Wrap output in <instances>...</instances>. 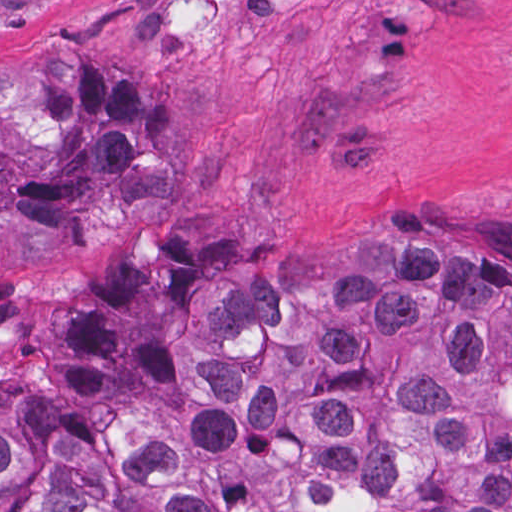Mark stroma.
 <instances>
[{
    "mask_svg": "<svg viewBox=\"0 0 512 512\" xmlns=\"http://www.w3.org/2000/svg\"><path fill=\"white\" fill-rule=\"evenodd\" d=\"M96 39L193 87L184 156L0 277L232 249L333 255L387 221L512 275V0H0V56Z\"/></svg>",
    "mask_w": 512,
    "mask_h": 512,
    "instance_id": "35a3bbf8",
    "label": "stroma"
}]
</instances>
